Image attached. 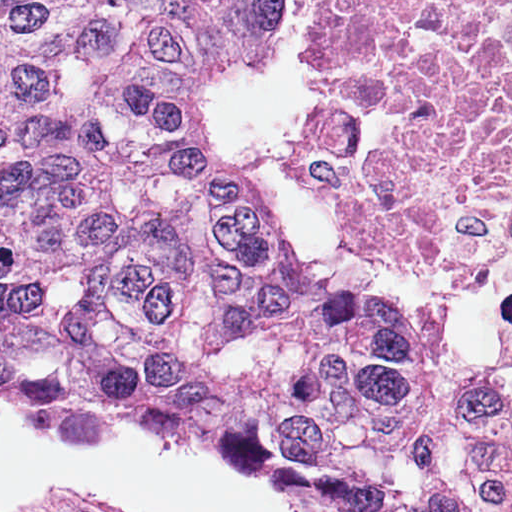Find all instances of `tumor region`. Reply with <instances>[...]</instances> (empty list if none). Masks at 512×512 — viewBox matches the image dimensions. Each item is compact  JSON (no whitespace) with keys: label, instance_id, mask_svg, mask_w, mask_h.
I'll return each mask as SVG.
<instances>
[{"label":"tumor region","instance_id":"e687c5a6","mask_svg":"<svg viewBox=\"0 0 512 512\" xmlns=\"http://www.w3.org/2000/svg\"><path fill=\"white\" fill-rule=\"evenodd\" d=\"M276 0H0V391L396 512L512 461V371L311 271L195 116Z\"/></svg>","mask_w":512,"mask_h":512}]
</instances>
